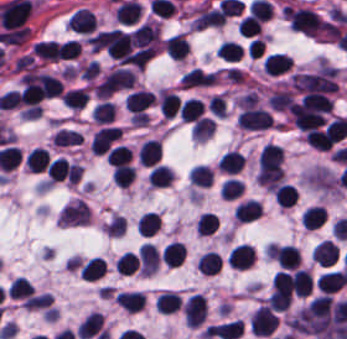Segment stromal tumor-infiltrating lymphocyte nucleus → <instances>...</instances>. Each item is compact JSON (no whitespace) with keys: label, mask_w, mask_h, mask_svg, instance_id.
Listing matches in <instances>:
<instances>
[{"label":"stromal tumor-infiltrating lymphocyte nucleus","mask_w":347,"mask_h":339,"mask_svg":"<svg viewBox=\"0 0 347 339\" xmlns=\"http://www.w3.org/2000/svg\"><path fill=\"white\" fill-rule=\"evenodd\" d=\"M278 323L274 313L263 305L254 311L248 325L254 336H268Z\"/></svg>","instance_id":"stromal-tumor-infiltrating-lymphocyte-nucleus-1"},{"label":"stromal tumor-infiltrating lymphocyte nucleus","mask_w":347,"mask_h":339,"mask_svg":"<svg viewBox=\"0 0 347 339\" xmlns=\"http://www.w3.org/2000/svg\"><path fill=\"white\" fill-rule=\"evenodd\" d=\"M237 122L238 127L246 129H264L271 125V119L266 110L249 105L241 110Z\"/></svg>","instance_id":"stromal-tumor-infiltrating-lymphocyte-nucleus-2"},{"label":"stromal tumor-infiltrating lymphocyte nucleus","mask_w":347,"mask_h":339,"mask_svg":"<svg viewBox=\"0 0 347 339\" xmlns=\"http://www.w3.org/2000/svg\"><path fill=\"white\" fill-rule=\"evenodd\" d=\"M185 324L201 325L206 318V298L201 294H193L182 307Z\"/></svg>","instance_id":"stromal-tumor-infiltrating-lymphocyte-nucleus-3"},{"label":"stromal tumor-infiltrating lymphocyte nucleus","mask_w":347,"mask_h":339,"mask_svg":"<svg viewBox=\"0 0 347 339\" xmlns=\"http://www.w3.org/2000/svg\"><path fill=\"white\" fill-rule=\"evenodd\" d=\"M119 128L107 126L95 131L91 138V150L96 153L105 152L119 135Z\"/></svg>","instance_id":"stromal-tumor-infiltrating-lymphocyte-nucleus-4"},{"label":"stromal tumor-infiltrating lymphocyte nucleus","mask_w":347,"mask_h":339,"mask_svg":"<svg viewBox=\"0 0 347 339\" xmlns=\"http://www.w3.org/2000/svg\"><path fill=\"white\" fill-rule=\"evenodd\" d=\"M243 330V322L232 320L208 327V338L235 339Z\"/></svg>","instance_id":"stromal-tumor-infiltrating-lymphocyte-nucleus-5"},{"label":"stromal tumor-infiltrating lymphocyte nucleus","mask_w":347,"mask_h":339,"mask_svg":"<svg viewBox=\"0 0 347 339\" xmlns=\"http://www.w3.org/2000/svg\"><path fill=\"white\" fill-rule=\"evenodd\" d=\"M311 256L315 263L328 267L335 264L338 250L331 240H324L314 247Z\"/></svg>","instance_id":"stromal-tumor-infiltrating-lymphocyte-nucleus-6"},{"label":"stromal tumor-infiltrating lymphocyte nucleus","mask_w":347,"mask_h":339,"mask_svg":"<svg viewBox=\"0 0 347 339\" xmlns=\"http://www.w3.org/2000/svg\"><path fill=\"white\" fill-rule=\"evenodd\" d=\"M153 99L154 96L152 92L147 90H134L124 100V106L136 116L148 108Z\"/></svg>","instance_id":"stromal-tumor-infiltrating-lymphocyte-nucleus-7"},{"label":"stromal tumor-infiltrating lymphocyte nucleus","mask_w":347,"mask_h":339,"mask_svg":"<svg viewBox=\"0 0 347 339\" xmlns=\"http://www.w3.org/2000/svg\"><path fill=\"white\" fill-rule=\"evenodd\" d=\"M32 50L36 57L46 61H58L62 59L61 45L53 40H40L34 44Z\"/></svg>","instance_id":"stromal-tumor-infiltrating-lymphocyte-nucleus-8"},{"label":"stromal tumor-infiltrating lymphocyte nucleus","mask_w":347,"mask_h":339,"mask_svg":"<svg viewBox=\"0 0 347 339\" xmlns=\"http://www.w3.org/2000/svg\"><path fill=\"white\" fill-rule=\"evenodd\" d=\"M323 209L317 205L306 206L300 216V223L305 230H314L325 221Z\"/></svg>","instance_id":"stromal-tumor-infiltrating-lymphocyte-nucleus-9"},{"label":"stromal tumor-infiltrating lymphocyte nucleus","mask_w":347,"mask_h":339,"mask_svg":"<svg viewBox=\"0 0 347 339\" xmlns=\"http://www.w3.org/2000/svg\"><path fill=\"white\" fill-rule=\"evenodd\" d=\"M138 156L141 165H154L160 157L159 139H145Z\"/></svg>","instance_id":"stromal-tumor-infiltrating-lymphocyte-nucleus-10"},{"label":"stromal tumor-infiltrating lymphocyte nucleus","mask_w":347,"mask_h":339,"mask_svg":"<svg viewBox=\"0 0 347 339\" xmlns=\"http://www.w3.org/2000/svg\"><path fill=\"white\" fill-rule=\"evenodd\" d=\"M244 162L243 155L235 149H228L224 152L218 160V167L220 171L229 173H237L242 167Z\"/></svg>","instance_id":"stromal-tumor-infiltrating-lymphocyte-nucleus-11"},{"label":"stromal tumor-infiltrating lymphocyte nucleus","mask_w":347,"mask_h":339,"mask_svg":"<svg viewBox=\"0 0 347 339\" xmlns=\"http://www.w3.org/2000/svg\"><path fill=\"white\" fill-rule=\"evenodd\" d=\"M186 248L177 242H170L161 251V258L166 267H178L183 261Z\"/></svg>","instance_id":"stromal-tumor-infiltrating-lymphocyte-nucleus-12"},{"label":"stromal tumor-infiltrating lymphocyte nucleus","mask_w":347,"mask_h":339,"mask_svg":"<svg viewBox=\"0 0 347 339\" xmlns=\"http://www.w3.org/2000/svg\"><path fill=\"white\" fill-rule=\"evenodd\" d=\"M156 311L170 313L176 311L181 305V296L176 292L164 291L154 300Z\"/></svg>","instance_id":"stromal-tumor-infiltrating-lymphocyte-nucleus-13"},{"label":"stromal tumor-infiltrating lymphocyte nucleus","mask_w":347,"mask_h":339,"mask_svg":"<svg viewBox=\"0 0 347 339\" xmlns=\"http://www.w3.org/2000/svg\"><path fill=\"white\" fill-rule=\"evenodd\" d=\"M188 50V42L185 35H171L166 40L165 52L174 60H182Z\"/></svg>","instance_id":"stromal-tumor-infiltrating-lymphocyte-nucleus-14"},{"label":"stromal tumor-infiltrating lymphocyte nucleus","mask_w":347,"mask_h":339,"mask_svg":"<svg viewBox=\"0 0 347 339\" xmlns=\"http://www.w3.org/2000/svg\"><path fill=\"white\" fill-rule=\"evenodd\" d=\"M261 206L256 200H247L237 205L234 216L241 222H252L260 216Z\"/></svg>","instance_id":"stromal-tumor-infiltrating-lymphocyte-nucleus-15"},{"label":"stromal tumor-infiltrating lymphocyte nucleus","mask_w":347,"mask_h":339,"mask_svg":"<svg viewBox=\"0 0 347 339\" xmlns=\"http://www.w3.org/2000/svg\"><path fill=\"white\" fill-rule=\"evenodd\" d=\"M291 288L299 297H306L312 290V281L306 270L298 269L291 277Z\"/></svg>","instance_id":"stromal-tumor-infiltrating-lymphocyte-nucleus-16"},{"label":"stromal tumor-infiltrating lymphocyte nucleus","mask_w":347,"mask_h":339,"mask_svg":"<svg viewBox=\"0 0 347 339\" xmlns=\"http://www.w3.org/2000/svg\"><path fill=\"white\" fill-rule=\"evenodd\" d=\"M292 60L283 54H269L263 61L264 68L269 75H277L290 68Z\"/></svg>","instance_id":"stromal-tumor-infiltrating-lymphocyte-nucleus-17"},{"label":"stromal tumor-infiltrating lymphocyte nucleus","mask_w":347,"mask_h":339,"mask_svg":"<svg viewBox=\"0 0 347 339\" xmlns=\"http://www.w3.org/2000/svg\"><path fill=\"white\" fill-rule=\"evenodd\" d=\"M203 102L196 97H189L180 106V116L182 122H193L201 116Z\"/></svg>","instance_id":"stromal-tumor-infiltrating-lymphocyte-nucleus-18"},{"label":"stromal tumor-infiltrating lymphocyte nucleus","mask_w":347,"mask_h":339,"mask_svg":"<svg viewBox=\"0 0 347 339\" xmlns=\"http://www.w3.org/2000/svg\"><path fill=\"white\" fill-rule=\"evenodd\" d=\"M342 283L340 275L336 271L324 272L317 277L316 285L320 293L331 294Z\"/></svg>","instance_id":"stromal-tumor-infiltrating-lymphocyte-nucleus-19"},{"label":"stromal tumor-infiltrating lymphocyte nucleus","mask_w":347,"mask_h":339,"mask_svg":"<svg viewBox=\"0 0 347 339\" xmlns=\"http://www.w3.org/2000/svg\"><path fill=\"white\" fill-rule=\"evenodd\" d=\"M25 160L27 170L39 173L48 164L46 149L34 148L25 155Z\"/></svg>","instance_id":"stromal-tumor-infiltrating-lymphocyte-nucleus-20"},{"label":"stromal tumor-infiltrating lymphocyte nucleus","mask_w":347,"mask_h":339,"mask_svg":"<svg viewBox=\"0 0 347 339\" xmlns=\"http://www.w3.org/2000/svg\"><path fill=\"white\" fill-rule=\"evenodd\" d=\"M105 269V262L99 257H92L79 268L82 279L94 280L101 276Z\"/></svg>","instance_id":"stromal-tumor-infiltrating-lymphocyte-nucleus-21"},{"label":"stromal tumor-infiltrating lymphocyte nucleus","mask_w":347,"mask_h":339,"mask_svg":"<svg viewBox=\"0 0 347 339\" xmlns=\"http://www.w3.org/2000/svg\"><path fill=\"white\" fill-rule=\"evenodd\" d=\"M273 193L277 204L285 209L292 206L296 199L294 186L291 185L279 184Z\"/></svg>","instance_id":"stromal-tumor-infiltrating-lymphocyte-nucleus-22"},{"label":"stromal tumor-infiltrating lymphocyte nucleus","mask_w":347,"mask_h":339,"mask_svg":"<svg viewBox=\"0 0 347 339\" xmlns=\"http://www.w3.org/2000/svg\"><path fill=\"white\" fill-rule=\"evenodd\" d=\"M191 184L209 186L212 181V171L208 165L195 164L189 173Z\"/></svg>","instance_id":"stromal-tumor-infiltrating-lymphocyte-nucleus-23"},{"label":"stromal tumor-infiltrating lymphocyte nucleus","mask_w":347,"mask_h":339,"mask_svg":"<svg viewBox=\"0 0 347 339\" xmlns=\"http://www.w3.org/2000/svg\"><path fill=\"white\" fill-rule=\"evenodd\" d=\"M135 176V169L126 164H118L113 168L112 180L115 185L129 186Z\"/></svg>","instance_id":"stromal-tumor-infiltrating-lymphocyte-nucleus-24"},{"label":"stromal tumor-infiltrating lymphocyte nucleus","mask_w":347,"mask_h":339,"mask_svg":"<svg viewBox=\"0 0 347 339\" xmlns=\"http://www.w3.org/2000/svg\"><path fill=\"white\" fill-rule=\"evenodd\" d=\"M216 52L226 61H235L242 53V46L237 41L223 40Z\"/></svg>","instance_id":"stromal-tumor-infiltrating-lymphocyte-nucleus-25"},{"label":"stromal tumor-infiltrating lymphocyte nucleus","mask_w":347,"mask_h":339,"mask_svg":"<svg viewBox=\"0 0 347 339\" xmlns=\"http://www.w3.org/2000/svg\"><path fill=\"white\" fill-rule=\"evenodd\" d=\"M87 93L85 89L76 88L66 91L61 99L65 106L69 108H82L87 100Z\"/></svg>","instance_id":"stromal-tumor-infiltrating-lymphocyte-nucleus-26"},{"label":"stromal tumor-infiltrating lymphocyte nucleus","mask_w":347,"mask_h":339,"mask_svg":"<svg viewBox=\"0 0 347 339\" xmlns=\"http://www.w3.org/2000/svg\"><path fill=\"white\" fill-rule=\"evenodd\" d=\"M115 106L113 102L100 101L93 109V119L98 123H108L113 119Z\"/></svg>","instance_id":"stromal-tumor-infiltrating-lymphocyte-nucleus-27"},{"label":"stromal tumor-infiltrating lymphocyte nucleus","mask_w":347,"mask_h":339,"mask_svg":"<svg viewBox=\"0 0 347 339\" xmlns=\"http://www.w3.org/2000/svg\"><path fill=\"white\" fill-rule=\"evenodd\" d=\"M171 180V169L155 164L150 172L149 183L153 186H167Z\"/></svg>","instance_id":"stromal-tumor-infiltrating-lymphocyte-nucleus-28"},{"label":"stromal tumor-infiltrating lymphocyte nucleus","mask_w":347,"mask_h":339,"mask_svg":"<svg viewBox=\"0 0 347 339\" xmlns=\"http://www.w3.org/2000/svg\"><path fill=\"white\" fill-rule=\"evenodd\" d=\"M137 257L134 253L124 252L120 255L115 262V269L117 273L129 275L136 269Z\"/></svg>","instance_id":"stromal-tumor-infiltrating-lymphocyte-nucleus-29"},{"label":"stromal tumor-infiltrating lymphocyte nucleus","mask_w":347,"mask_h":339,"mask_svg":"<svg viewBox=\"0 0 347 339\" xmlns=\"http://www.w3.org/2000/svg\"><path fill=\"white\" fill-rule=\"evenodd\" d=\"M130 150L128 147L117 145L109 153L107 164L118 165L125 161H128Z\"/></svg>","instance_id":"stromal-tumor-infiltrating-lymphocyte-nucleus-30"}]
</instances>
